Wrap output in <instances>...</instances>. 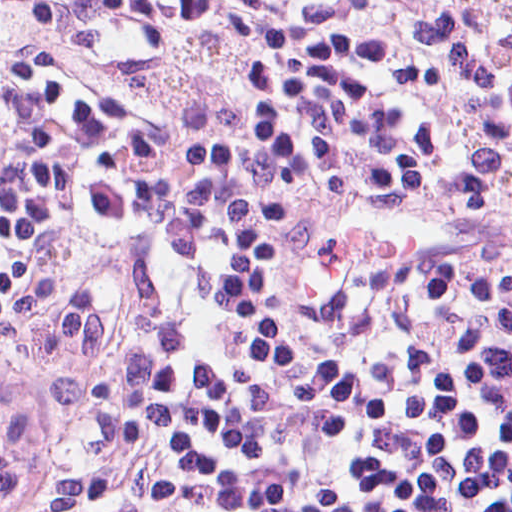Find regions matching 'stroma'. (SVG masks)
<instances>
[{"label":"stroma","instance_id":"1","mask_svg":"<svg viewBox=\"0 0 512 512\" xmlns=\"http://www.w3.org/2000/svg\"><path fill=\"white\" fill-rule=\"evenodd\" d=\"M42 1H512V0H0V59Z\"/></svg>","mask_w":512,"mask_h":512}]
</instances>
